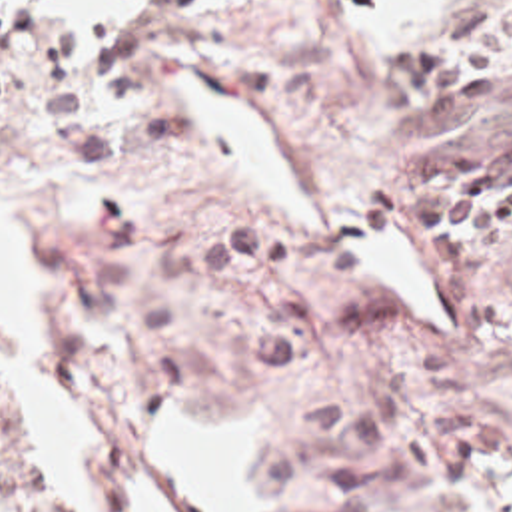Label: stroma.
<instances>
[{
  "instance_id": "1",
  "label": "stroma",
  "mask_w": 512,
  "mask_h": 512,
  "mask_svg": "<svg viewBox=\"0 0 512 512\" xmlns=\"http://www.w3.org/2000/svg\"><path fill=\"white\" fill-rule=\"evenodd\" d=\"M6 1L34 45L0 101V200L64 358L22 352L109 436L107 512H131L127 474L167 512H199L145 432L169 408L247 402L253 512H493L512 476V242L445 268L407 224L401 168L411 142L512 135V67L471 115H393L373 103L387 47L353 37L343 0H125L82 41H46L36 1ZM179 67L275 127L327 238L221 164L167 79ZM389 224L431 258L443 328L345 254ZM0 512H74L2 390Z\"/></svg>"
}]
</instances>
